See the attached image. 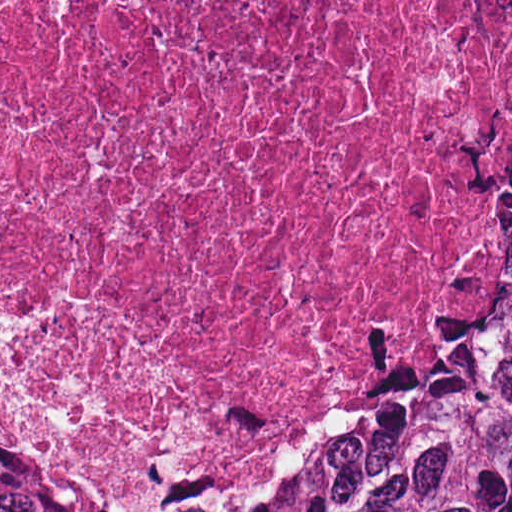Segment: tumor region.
<instances>
[{"label": "tumor region", "instance_id": "1", "mask_svg": "<svg viewBox=\"0 0 512 512\" xmlns=\"http://www.w3.org/2000/svg\"><path fill=\"white\" fill-rule=\"evenodd\" d=\"M0 512H512V70L469 209L292 468L128 473L0 406Z\"/></svg>", "mask_w": 512, "mask_h": 512}]
</instances>
